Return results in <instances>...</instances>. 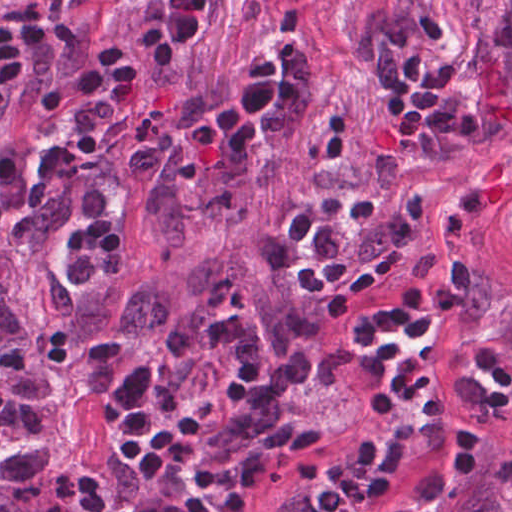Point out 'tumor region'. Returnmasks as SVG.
<instances>
[{"label": "tumor region", "instance_id": "1", "mask_svg": "<svg viewBox=\"0 0 512 512\" xmlns=\"http://www.w3.org/2000/svg\"><path fill=\"white\" fill-rule=\"evenodd\" d=\"M492 318L495 340L512 366V288L505 292L484 283L481 275L472 300L459 312L454 331L465 334ZM473 447L459 471L424 512H512V438L500 466L497 445L489 439L487 454Z\"/></svg>", "mask_w": 512, "mask_h": 512}]
</instances>
